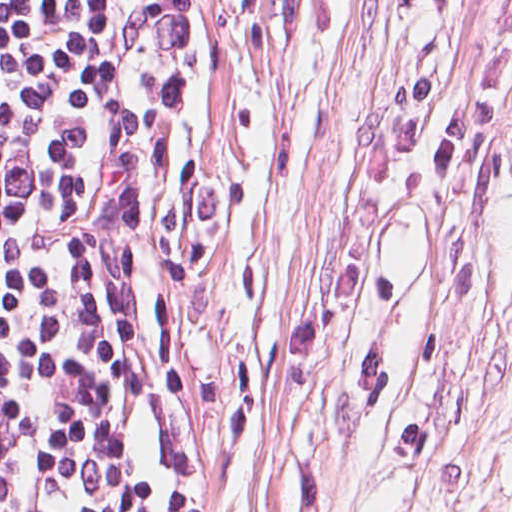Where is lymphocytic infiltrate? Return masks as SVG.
<instances>
[{"mask_svg":"<svg viewBox=\"0 0 512 512\" xmlns=\"http://www.w3.org/2000/svg\"><path fill=\"white\" fill-rule=\"evenodd\" d=\"M168 0H0V512H136Z\"/></svg>","mask_w":512,"mask_h":512,"instance_id":"1","label":"lymphocytic infiltrate"}]
</instances>
